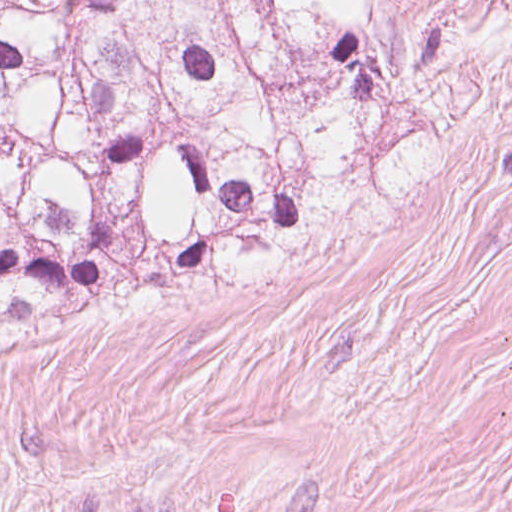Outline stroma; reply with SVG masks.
<instances>
[{
    "mask_svg": "<svg viewBox=\"0 0 512 512\" xmlns=\"http://www.w3.org/2000/svg\"><path fill=\"white\" fill-rule=\"evenodd\" d=\"M464 40L451 153L321 247L0 334V512H512V0H390Z\"/></svg>",
    "mask_w": 512,
    "mask_h": 512,
    "instance_id": "obj_1",
    "label": "stroma"
}]
</instances>
